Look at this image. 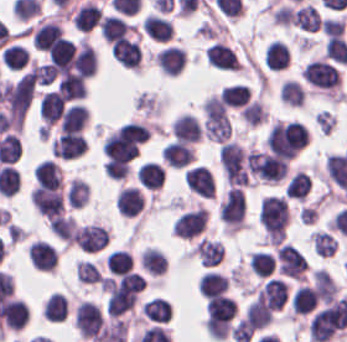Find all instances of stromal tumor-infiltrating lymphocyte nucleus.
<instances>
[{"label": "stromal tumor-infiltrating lymphocyte nucleus", "instance_id": "a6e9041d", "mask_svg": "<svg viewBox=\"0 0 347 342\" xmlns=\"http://www.w3.org/2000/svg\"><path fill=\"white\" fill-rule=\"evenodd\" d=\"M100 34L110 41L125 36L132 26L117 15L105 14L98 24Z\"/></svg>", "mask_w": 347, "mask_h": 342}, {"label": "stromal tumor-infiltrating lymphocyte nucleus", "instance_id": "bc302bb0", "mask_svg": "<svg viewBox=\"0 0 347 342\" xmlns=\"http://www.w3.org/2000/svg\"><path fill=\"white\" fill-rule=\"evenodd\" d=\"M347 321V304L335 296L310 317L307 330L311 341L325 342L340 331Z\"/></svg>", "mask_w": 347, "mask_h": 342}, {"label": "stromal tumor-infiltrating lymphocyte nucleus", "instance_id": "6da75f8f", "mask_svg": "<svg viewBox=\"0 0 347 342\" xmlns=\"http://www.w3.org/2000/svg\"><path fill=\"white\" fill-rule=\"evenodd\" d=\"M66 201L75 207L84 206L88 202V182L79 177H72L66 186Z\"/></svg>", "mask_w": 347, "mask_h": 342}, {"label": "stromal tumor-infiltrating lymphocyte nucleus", "instance_id": "83f04bf1", "mask_svg": "<svg viewBox=\"0 0 347 342\" xmlns=\"http://www.w3.org/2000/svg\"><path fill=\"white\" fill-rule=\"evenodd\" d=\"M263 60L269 69H282L289 60V48L279 40H271L265 46Z\"/></svg>", "mask_w": 347, "mask_h": 342}, {"label": "stromal tumor-infiltrating lymphocyte nucleus", "instance_id": "e9af9c67", "mask_svg": "<svg viewBox=\"0 0 347 342\" xmlns=\"http://www.w3.org/2000/svg\"><path fill=\"white\" fill-rule=\"evenodd\" d=\"M143 196L134 186H120L115 193L114 207L118 214L132 217L139 212Z\"/></svg>", "mask_w": 347, "mask_h": 342}, {"label": "stromal tumor-infiltrating lymphocyte nucleus", "instance_id": "c26a33f6", "mask_svg": "<svg viewBox=\"0 0 347 342\" xmlns=\"http://www.w3.org/2000/svg\"><path fill=\"white\" fill-rule=\"evenodd\" d=\"M64 106L63 98L53 89H46L37 107L38 117L42 125L49 126L61 113Z\"/></svg>", "mask_w": 347, "mask_h": 342}, {"label": "stromal tumor-infiltrating lymphocyte nucleus", "instance_id": "21d57d70", "mask_svg": "<svg viewBox=\"0 0 347 342\" xmlns=\"http://www.w3.org/2000/svg\"><path fill=\"white\" fill-rule=\"evenodd\" d=\"M164 162L170 166H180L193 156L192 146L183 140H170L160 152Z\"/></svg>", "mask_w": 347, "mask_h": 342}, {"label": "stromal tumor-infiltrating lymphocyte nucleus", "instance_id": "b01e43ef", "mask_svg": "<svg viewBox=\"0 0 347 342\" xmlns=\"http://www.w3.org/2000/svg\"><path fill=\"white\" fill-rule=\"evenodd\" d=\"M100 271L91 260L78 259L76 263V277L80 282H99Z\"/></svg>", "mask_w": 347, "mask_h": 342}, {"label": "stromal tumor-infiltrating lymphocyte nucleus", "instance_id": "3290ff9b", "mask_svg": "<svg viewBox=\"0 0 347 342\" xmlns=\"http://www.w3.org/2000/svg\"><path fill=\"white\" fill-rule=\"evenodd\" d=\"M218 160L229 186H248L249 169L244 148L226 141L221 145Z\"/></svg>", "mask_w": 347, "mask_h": 342}, {"label": "stromal tumor-infiltrating lymphocyte nucleus", "instance_id": "6c763739", "mask_svg": "<svg viewBox=\"0 0 347 342\" xmlns=\"http://www.w3.org/2000/svg\"><path fill=\"white\" fill-rule=\"evenodd\" d=\"M193 248L204 266L218 264L223 254V244L217 238L201 236Z\"/></svg>", "mask_w": 347, "mask_h": 342}, {"label": "stromal tumor-infiltrating lymphocyte nucleus", "instance_id": "cac63f63", "mask_svg": "<svg viewBox=\"0 0 347 342\" xmlns=\"http://www.w3.org/2000/svg\"><path fill=\"white\" fill-rule=\"evenodd\" d=\"M204 57L214 68L238 70L240 61L231 49L221 42H213L204 48Z\"/></svg>", "mask_w": 347, "mask_h": 342}, {"label": "stromal tumor-infiltrating lymphocyte nucleus", "instance_id": "0ca4a824", "mask_svg": "<svg viewBox=\"0 0 347 342\" xmlns=\"http://www.w3.org/2000/svg\"><path fill=\"white\" fill-rule=\"evenodd\" d=\"M57 90L68 99H77L84 95V84L60 78L57 81Z\"/></svg>", "mask_w": 347, "mask_h": 342}, {"label": "stromal tumor-infiltrating lymphocyte nucleus", "instance_id": "4803ca6d", "mask_svg": "<svg viewBox=\"0 0 347 342\" xmlns=\"http://www.w3.org/2000/svg\"><path fill=\"white\" fill-rule=\"evenodd\" d=\"M274 255L276 269L293 279H302L307 263L299 249L283 242L275 247Z\"/></svg>", "mask_w": 347, "mask_h": 342}, {"label": "stromal tumor-infiltrating lymphocyte nucleus", "instance_id": "84afeb40", "mask_svg": "<svg viewBox=\"0 0 347 342\" xmlns=\"http://www.w3.org/2000/svg\"><path fill=\"white\" fill-rule=\"evenodd\" d=\"M291 20L300 29L315 32L320 27L321 16L309 2L294 9Z\"/></svg>", "mask_w": 347, "mask_h": 342}, {"label": "stromal tumor-infiltrating lymphocyte nucleus", "instance_id": "c8d0df70", "mask_svg": "<svg viewBox=\"0 0 347 342\" xmlns=\"http://www.w3.org/2000/svg\"><path fill=\"white\" fill-rule=\"evenodd\" d=\"M228 287V279L214 270H207L200 276L198 290L201 295L219 294Z\"/></svg>", "mask_w": 347, "mask_h": 342}, {"label": "stromal tumor-infiltrating lymphocyte nucleus", "instance_id": "fa64b396", "mask_svg": "<svg viewBox=\"0 0 347 342\" xmlns=\"http://www.w3.org/2000/svg\"><path fill=\"white\" fill-rule=\"evenodd\" d=\"M101 18V10L94 1H86L78 6L71 22L78 31H88L98 25Z\"/></svg>", "mask_w": 347, "mask_h": 342}, {"label": "stromal tumor-infiltrating lymphocyte nucleus", "instance_id": "9e4306bb", "mask_svg": "<svg viewBox=\"0 0 347 342\" xmlns=\"http://www.w3.org/2000/svg\"><path fill=\"white\" fill-rule=\"evenodd\" d=\"M109 53L121 67L137 69L140 52L139 46L134 40L122 36L114 38L109 43Z\"/></svg>", "mask_w": 347, "mask_h": 342}, {"label": "stromal tumor-infiltrating lymphocyte nucleus", "instance_id": "f3e2335f", "mask_svg": "<svg viewBox=\"0 0 347 342\" xmlns=\"http://www.w3.org/2000/svg\"><path fill=\"white\" fill-rule=\"evenodd\" d=\"M245 213L243 188L231 186L218 204V215L226 229H239Z\"/></svg>", "mask_w": 347, "mask_h": 342}, {"label": "stromal tumor-infiltrating lymphocyte nucleus", "instance_id": "04cf8593", "mask_svg": "<svg viewBox=\"0 0 347 342\" xmlns=\"http://www.w3.org/2000/svg\"><path fill=\"white\" fill-rule=\"evenodd\" d=\"M170 132L177 140L197 141L202 135L200 122L192 113H178L170 125Z\"/></svg>", "mask_w": 347, "mask_h": 342}, {"label": "stromal tumor-infiltrating lymphocyte nucleus", "instance_id": "2a367800", "mask_svg": "<svg viewBox=\"0 0 347 342\" xmlns=\"http://www.w3.org/2000/svg\"><path fill=\"white\" fill-rule=\"evenodd\" d=\"M103 323L104 319L98 304L89 300L78 303L74 313V327L80 335L94 339Z\"/></svg>", "mask_w": 347, "mask_h": 342}, {"label": "stromal tumor-infiltrating lymphocyte nucleus", "instance_id": "894b7857", "mask_svg": "<svg viewBox=\"0 0 347 342\" xmlns=\"http://www.w3.org/2000/svg\"><path fill=\"white\" fill-rule=\"evenodd\" d=\"M245 312L250 326L255 330L271 320V310L259 300H252L245 306Z\"/></svg>", "mask_w": 347, "mask_h": 342}, {"label": "stromal tumor-infiltrating lymphocyte nucleus", "instance_id": "7b516f1d", "mask_svg": "<svg viewBox=\"0 0 347 342\" xmlns=\"http://www.w3.org/2000/svg\"><path fill=\"white\" fill-rule=\"evenodd\" d=\"M218 95L228 106H241L250 99V87L245 83L234 82L222 88Z\"/></svg>", "mask_w": 347, "mask_h": 342}, {"label": "stromal tumor-infiltrating lymphocyte nucleus", "instance_id": "50b3126c", "mask_svg": "<svg viewBox=\"0 0 347 342\" xmlns=\"http://www.w3.org/2000/svg\"><path fill=\"white\" fill-rule=\"evenodd\" d=\"M0 58L6 69L17 70L25 65L28 54L24 46L12 42L1 50Z\"/></svg>", "mask_w": 347, "mask_h": 342}, {"label": "stromal tumor-infiltrating lymphocyte nucleus", "instance_id": "a5eb4a43", "mask_svg": "<svg viewBox=\"0 0 347 342\" xmlns=\"http://www.w3.org/2000/svg\"><path fill=\"white\" fill-rule=\"evenodd\" d=\"M44 312L49 321H63L65 317V297L60 291H53L44 300Z\"/></svg>", "mask_w": 347, "mask_h": 342}, {"label": "stromal tumor-infiltrating lymphocyte nucleus", "instance_id": "57c3b739", "mask_svg": "<svg viewBox=\"0 0 347 342\" xmlns=\"http://www.w3.org/2000/svg\"><path fill=\"white\" fill-rule=\"evenodd\" d=\"M310 238L315 254L319 256H331L334 254L337 239L332 235L315 229L310 233Z\"/></svg>", "mask_w": 347, "mask_h": 342}, {"label": "stromal tumor-infiltrating lymphocyte nucleus", "instance_id": "52c7bb5b", "mask_svg": "<svg viewBox=\"0 0 347 342\" xmlns=\"http://www.w3.org/2000/svg\"><path fill=\"white\" fill-rule=\"evenodd\" d=\"M289 209L282 195H266L260 198L258 220L265 240L277 244L285 235Z\"/></svg>", "mask_w": 347, "mask_h": 342}, {"label": "stromal tumor-infiltrating lymphocyte nucleus", "instance_id": "fc20714e", "mask_svg": "<svg viewBox=\"0 0 347 342\" xmlns=\"http://www.w3.org/2000/svg\"><path fill=\"white\" fill-rule=\"evenodd\" d=\"M109 274H122L131 268V259L125 249H111L104 257Z\"/></svg>", "mask_w": 347, "mask_h": 342}, {"label": "stromal tumor-infiltrating lymphocyte nucleus", "instance_id": "9ea309e8", "mask_svg": "<svg viewBox=\"0 0 347 342\" xmlns=\"http://www.w3.org/2000/svg\"><path fill=\"white\" fill-rule=\"evenodd\" d=\"M306 83L314 88L332 93L338 83L337 68L326 59L312 58L305 63L300 72Z\"/></svg>", "mask_w": 347, "mask_h": 342}, {"label": "stromal tumor-infiltrating lymphocyte nucleus", "instance_id": "ccc9de39", "mask_svg": "<svg viewBox=\"0 0 347 342\" xmlns=\"http://www.w3.org/2000/svg\"><path fill=\"white\" fill-rule=\"evenodd\" d=\"M316 304L312 286L300 284L291 295L290 310L293 313H306Z\"/></svg>", "mask_w": 347, "mask_h": 342}, {"label": "stromal tumor-infiltrating lymphocyte nucleus", "instance_id": "3c572f05", "mask_svg": "<svg viewBox=\"0 0 347 342\" xmlns=\"http://www.w3.org/2000/svg\"><path fill=\"white\" fill-rule=\"evenodd\" d=\"M255 299L271 310H279L285 302L286 283L269 276L254 292Z\"/></svg>", "mask_w": 347, "mask_h": 342}, {"label": "stromal tumor-infiltrating lymphocyte nucleus", "instance_id": "8379cbfb", "mask_svg": "<svg viewBox=\"0 0 347 342\" xmlns=\"http://www.w3.org/2000/svg\"><path fill=\"white\" fill-rule=\"evenodd\" d=\"M314 292L320 302L327 303L336 296V284L325 268L310 273Z\"/></svg>", "mask_w": 347, "mask_h": 342}, {"label": "stromal tumor-infiltrating lymphocyte nucleus", "instance_id": "83bf90d3", "mask_svg": "<svg viewBox=\"0 0 347 342\" xmlns=\"http://www.w3.org/2000/svg\"><path fill=\"white\" fill-rule=\"evenodd\" d=\"M240 115L250 125H256L265 121L267 113L262 104L255 98L249 100L244 106L239 109Z\"/></svg>", "mask_w": 347, "mask_h": 342}, {"label": "stromal tumor-infiltrating lymphocyte nucleus", "instance_id": "16295066", "mask_svg": "<svg viewBox=\"0 0 347 342\" xmlns=\"http://www.w3.org/2000/svg\"><path fill=\"white\" fill-rule=\"evenodd\" d=\"M136 176L141 186L155 189L161 186L163 169L157 161L144 160Z\"/></svg>", "mask_w": 347, "mask_h": 342}, {"label": "stromal tumor-infiltrating lymphocyte nucleus", "instance_id": "4c9ddf68", "mask_svg": "<svg viewBox=\"0 0 347 342\" xmlns=\"http://www.w3.org/2000/svg\"><path fill=\"white\" fill-rule=\"evenodd\" d=\"M108 239V228L93 222L76 227L73 233V242L80 250L98 251Z\"/></svg>", "mask_w": 347, "mask_h": 342}, {"label": "stromal tumor-infiltrating lymphocyte nucleus", "instance_id": "1d375fb5", "mask_svg": "<svg viewBox=\"0 0 347 342\" xmlns=\"http://www.w3.org/2000/svg\"><path fill=\"white\" fill-rule=\"evenodd\" d=\"M140 312L149 320L166 322L171 314L167 300L163 296H150L140 305Z\"/></svg>", "mask_w": 347, "mask_h": 342}, {"label": "stromal tumor-infiltrating lymphocyte nucleus", "instance_id": "782c7336", "mask_svg": "<svg viewBox=\"0 0 347 342\" xmlns=\"http://www.w3.org/2000/svg\"><path fill=\"white\" fill-rule=\"evenodd\" d=\"M28 319V306L18 298L9 297L1 309V323L10 330H19Z\"/></svg>", "mask_w": 347, "mask_h": 342}, {"label": "stromal tumor-infiltrating lymphocyte nucleus", "instance_id": "2761f720", "mask_svg": "<svg viewBox=\"0 0 347 342\" xmlns=\"http://www.w3.org/2000/svg\"><path fill=\"white\" fill-rule=\"evenodd\" d=\"M206 222L207 214L200 206L176 217L171 224V233L180 238H192L200 233Z\"/></svg>", "mask_w": 347, "mask_h": 342}, {"label": "stromal tumor-infiltrating lymphocyte nucleus", "instance_id": "abfb95fc", "mask_svg": "<svg viewBox=\"0 0 347 342\" xmlns=\"http://www.w3.org/2000/svg\"><path fill=\"white\" fill-rule=\"evenodd\" d=\"M245 155L250 172L269 182H277L282 177L289 161L267 150H248Z\"/></svg>", "mask_w": 347, "mask_h": 342}, {"label": "stromal tumor-infiltrating lymphocyte nucleus", "instance_id": "02f42fee", "mask_svg": "<svg viewBox=\"0 0 347 342\" xmlns=\"http://www.w3.org/2000/svg\"><path fill=\"white\" fill-rule=\"evenodd\" d=\"M37 183L57 186L63 181L60 166L50 157H43L32 171Z\"/></svg>", "mask_w": 347, "mask_h": 342}, {"label": "stromal tumor-infiltrating lymphocyte nucleus", "instance_id": "afbf053c", "mask_svg": "<svg viewBox=\"0 0 347 342\" xmlns=\"http://www.w3.org/2000/svg\"><path fill=\"white\" fill-rule=\"evenodd\" d=\"M140 263L150 275H160L167 266L165 253L155 245H147L141 250Z\"/></svg>", "mask_w": 347, "mask_h": 342}, {"label": "stromal tumor-infiltrating lymphocyte nucleus", "instance_id": "4245b91a", "mask_svg": "<svg viewBox=\"0 0 347 342\" xmlns=\"http://www.w3.org/2000/svg\"><path fill=\"white\" fill-rule=\"evenodd\" d=\"M85 150V140L79 130H66L51 140L49 151L54 157L70 159Z\"/></svg>", "mask_w": 347, "mask_h": 342}, {"label": "stromal tumor-infiltrating lymphocyte nucleus", "instance_id": "42bb06b2", "mask_svg": "<svg viewBox=\"0 0 347 342\" xmlns=\"http://www.w3.org/2000/svg\"><path fill=\"white\" fill-rule=\"evenodd\" d=\"M182 177L187 187L198 196L212 198L214 194L212 172L204 164L187 167Z\"/></svg>", "mask_w": 347, "mask_h": 342}, {"label": "stromal tumor-infiltrating lymphocyte nucleus", "instance_id": "4aeada98", "mask_svg": "<svg viewBox=\"0 0 347 342\" xmlns=\"http://www.w3.org/2000/svg\"><path fill=\"white\" fill-rule=\"evenodd\" d=\"M344 19L341 17L324 16L320 26L326 36L338 34L343 29Z\"/></svg>", "mask_w": 347, "mask_h": 342}, {"label": "stromal tumor-infiltrating lymphocyte nucleus", "instance_id": "023d44f5", "mask_svg": "<svg viewBox=\"0 0 347 342\" xmlns=\"http://www.w3.org/2000/svg\"><path fill=\"white\" fill-rule=\"evenodd\" d=\"M74 52L73 41L69 38L58 37L51 42L46 50L48 62L69 66Z\"/></svg>", "mask_w": 347, "mask_h": 342}, {"label": "stromal tumor-infiltrating lymphocyte nucleus", "instance_id": "18da8d3c", "mask_svg": "<svg viewBox=\"0 0 347 342\" xmlns=\"http://www.w3.org/2000/svg\"><path fill=\"white\" fill-rule=\"evenodd\" d=\"M88 116L86 105L79 102H72L64 107L58 119L59 129L72 130L79 129Z\"/></svg>", "mask_w": 347, "mask_h": 342}, {"label": "stromal tumor-infiltrating lymphocyte nucleus", "instance_id": "3e0999b9", "mask_svg": "<svg viewBox=\"0 0 347 342\" xmlns=\"http://www.w3.org/2000/svg\"><path fill=\"white\" fill-rule=\"evenodd\" d=\"M73 61L74 69L78 73L89 77L94 74L96 50L85 38H78L73 52Z\"/></svg>", "mask_w": 347, "mask_h": 342}, {"label": "stromal tumor-infiltrating lymphocyte nucleus", "instance_id": "741cfc7e", "mask_svg": "<svg viewBox=\"0 0 347 342\" xmlns=\"http://www.w3.org/2000/svg\"><path fill=\"white\" fill-rule=\"evenodd\" d=\"M36 83L40 85H48L55 77L52 64L49 63H33L31 67Z\"/></svg>", "mask_w": 347, "mask_h": 342}, {"label": "stromal tumor-infiltrating lymphocyte nucleus", "instance_id": "a0a3295f", "mask_svg": "<svg viewBox=\"0 0 347 342\" xmlns=\"http://www.w3.org/2000/svg\"><path fill=\"white\" fill-rule=\"evenodd\" d=\"M60 25L54 19H38L32 34L33 47L47 50L59 37Z\"/></svg>", "mask_w": 347, "mask_h": 342}, {"label": "stromal tumor-infiltrating lymphocyte nucleus", "instance_id": "526d6599", "mask_svg": "<svg viewBox=\"0 0 347 342\" xmlns=\"http://www.w3.org/2000/svg\"><path fill=\"white\" fill-rule=\"evenodd\" d=\"M279 95L287 103L300 106L305 92L296 79L286 78L280 87Z\"/></svg>", "mask_w": 347, "mask_h": 342}, {"label": "stromal tumor-infiltrating lymphocyte nucleus", "instance_id": "a33fdf23", "mask_svg": "<svg viewBox=\"0 0 347 342\" xmlns=\"http://www.w3.org/2000/svg\"><path fill=\"white\" fill-rule=\"evenodd\" d=\"M247 264L250 273L255 276H266L274 268V257L263 249L248 253Z\"/></svg>", "mask_w": 347, "mask_h": 342}, {"label": "stromal tumor-infiltrating lymphocyte nucleus", "instance_id": "fb6c686a", "mask_svg": "<svg viewBox=\"0 0 347 342\" xmlns=\"http://www.w3.org/2000/svg\"><path fill=\"white\" fill-rule=\"evenodd\" d=\"M310 187L308 176L302 170H295L284 185L286 196L304 198Z\"/></svg>", "mask_w": 347, "mask_h": 342}, {"label": "stromal tumor-infiltrating lymphocyte nucleus", "instance_id": "2e467ee5", "mask_svg": "<svg viewBox=\"0 0 347 342\" xmlns=\"http://www.w3.org/2000/svg\"><path fill=\"white\" fill-rule=\"evenodd\" d=\"M32 266L38 269L53 270L57 262V252L43 238H36L27 247Z\"/></svg>", "mask_w": 347, "mask_h": 342}, {"label": "stromal tumor-infiltrating lymphocyte nucleus", "instance_id": "4f13568d", "mask_svg": "<svg viewBox=\"0 0 347 342\" xmlns=\"http://www.w3.org/2000/svg\"><path fill=\"white\" fill-rule=\"evenodd\" d=\"M32 204L46 218L62 214L63 192L58 185L37 183L30 196Z\"/></svg>", "mask_w": 347, "mask_h": 342}, {"label": "stromal tumor-infiltrating lymphocyte nucleus", "instance_id": "b6af03f8", "mask_svg": "<svg viewBox=\"0 0 347 342\" xmlns=\"http://www.w3.org/2000/svg\"><path fill=\"white\" fill-rule=\"evenodd\" d=\"M145 33L159 41H167L171 37V20L157 12H149L141 21Z\"/></svg>", "mask_w": 347, "mask_h": 342}, {"label": "stromal tumor-infiltrating lymphocyte nucleus", "instance_id": "7eef579d", "mask_svg": "<svg viewBox=\"0 0 347 342\" xmlns=\"http://www.w3.org/2000/svg\"><path fill=\"white\" fill-rule=\"evenodd\" d=\"M154 59L161 73L174 75L183 68L186 55L184 48L169 45L159 48Z\"/></svg>", "mask_w": 347, "mask_h": 342}]
</instances>
